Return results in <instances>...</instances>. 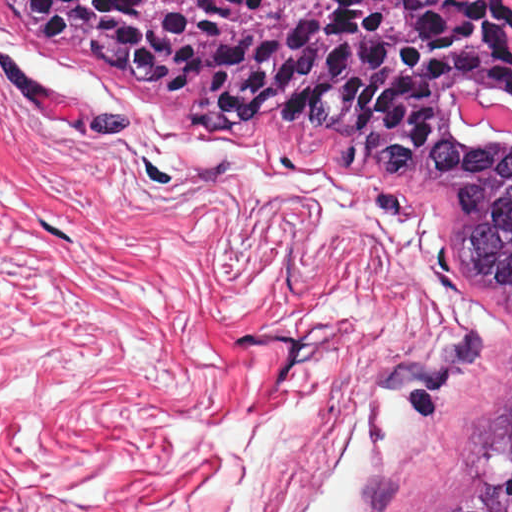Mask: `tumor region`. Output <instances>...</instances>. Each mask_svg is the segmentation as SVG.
<instances>
[{
  "mask_svg": "<svg viewBox=\"0 0 512 512\" xmlns=\"http://www.w3.org/2000/svg\"><path fill=\"white\" fill-rule=\"evenodd\" d=\"M0 16L132 94L81 125L105 143L166 111L185 138L433 227L471 328L402 375L408 415L453 409L473 364L500 351L463 447L412 512H512V144L453 109L512 104V0H0Z\"/></svg>",
  "mask_w": 512,
  "mask_h": 512,
  "instance_id": "tumor-region-1",
  "label": "tumor region"
}]
</instances>
